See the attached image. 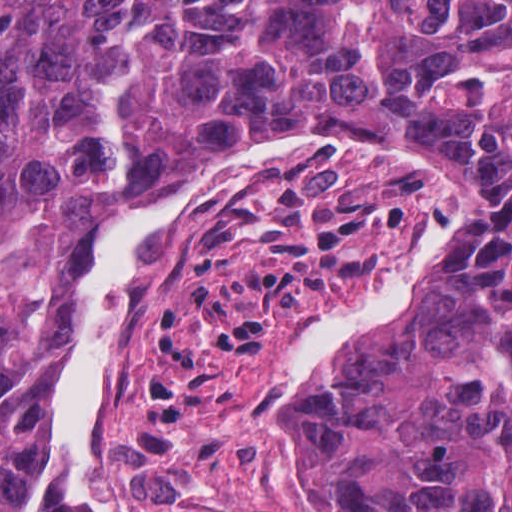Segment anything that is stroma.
Listing matches in <instances>:
<instances>
[{"mask_svg":"<svg viewBox=\"0 0 512 512\" xmlns=\"http://www.w3.org/2000/svg\"><path fill=\"white\" fill-rule=\"evenodd\" d=\"M475 193L480 212L433 277L484 229L496 195L452 148L346 147L179 225L128 321L94 430L111 511L299 512L265 424L267 378L315 313L373 279L433 214ZM69 289L26 337L34 437ZM344 342L305 376L299 478L342 512H387L356 480L332 411Z\"/></svg>","mask_w":512,"mask_h":512,"instance_id":"stroma-1","label":"stroma"}]
</instances>
